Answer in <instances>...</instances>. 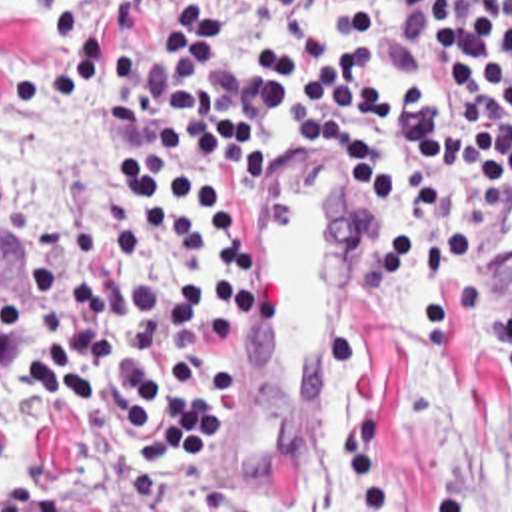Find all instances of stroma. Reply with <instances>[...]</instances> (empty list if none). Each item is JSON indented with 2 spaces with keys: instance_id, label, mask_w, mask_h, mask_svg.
Wrapping results in <instances>:
<instances>
[{
  "instance_id": "1",
  "label": "stroma",
  "mask_w": 512,
  "mask_h": 512,
  "mask_svg": "<svg viewBox=\"0 0 512 512\" xmlns=\"http://www.w3.org/2000/svg\"><path fill=\"white\" fill-rule=\"evenodd\" d=\"M19 5L15 0L0 11V47L15 61L11 89L55 71L65 43L105 29L135 7H93L79 33L49 45L37 39L35 13ZM81 95L107 105V75ZM111 129L107 119L105 217L89 229L93 245L113 223ZM290 185L310 183L262 181L258 189V369L232 437L173 487L155 485L119 461L97 427L57 407L39 371L0 367V417L13 429V467L0 477V512H272L294 497L302 485V379L294 339L266 291L276 205ZM314 187L334 199L332 191ZM336 209L346 239V295L330 337L354 389L346 443L366 481V509L440 512L448 495L446 419L470 405L484 423V512H512L510 379L456 313V359L424 351L418 253L384 297L356 293L362 219L354 207L336 203ZM45 231L29 233L17 249H0V283L25 315V281ZM51 231L73 241L75 231ZM494 251L512 283V209L494 219Z\"/></svg>"
}]
</instances>
